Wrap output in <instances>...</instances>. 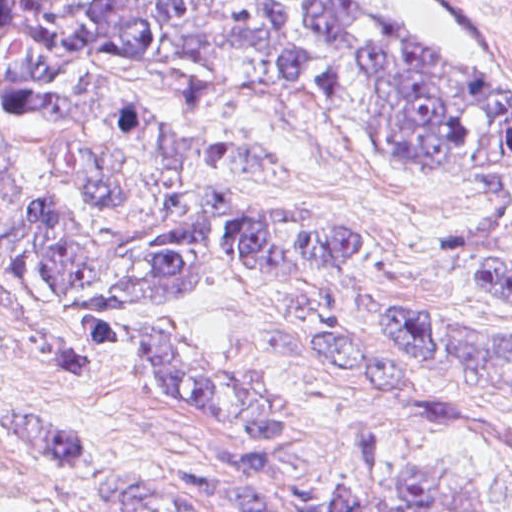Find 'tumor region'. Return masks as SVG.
I'll list each match as a JSON object with an SVG mask.
<instances>
[{"label":"tumor region","instance_id":"obj_1","mask_svg":"<svg viewBox=\"0 0 512 512\" xmlns=\"http://www.w3.org/2000/svg\"><path fill=\"white\" fill-rule=\"evenodd\" d=\"M249 87H293L485 199L483 247L440 267L512 310V80L355 0H0V321L174 397L221 476L143 468L71 428L0 414V448L278 512L283 408L220 349L141 322L203 276L298 301L308 362L351 399L339 462L295 512H476L479 486L393 444L468 418L353 342L336 308L366 260H402L324 208L253 133ZM388 330L472 389H512V340L400 312Z\"/></svg>","mask_w":512,"mask_h":512}]
</instances>
